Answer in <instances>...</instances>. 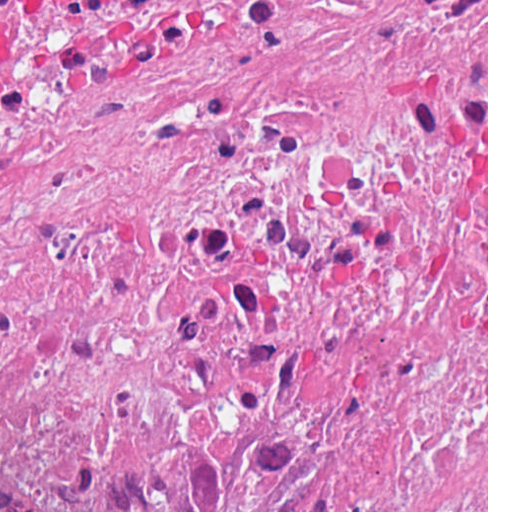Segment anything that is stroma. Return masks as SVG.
<instances>
[{
    "instance_id": "35a3bbf8",
    "label": "stroma",
    "mask_w": 512,
    "mask_h": 512,
    "mask_svg": "<svg viewBox=\"0 0 512 512\" xmlns=\"http://www.w3.org/2000/svg\"><path fill=\"white\" fill-rule=\"evenodd\" d=\"M486 414L488 512V0H438V411L412 424Z\"/></svg>"
}]
</instances>
